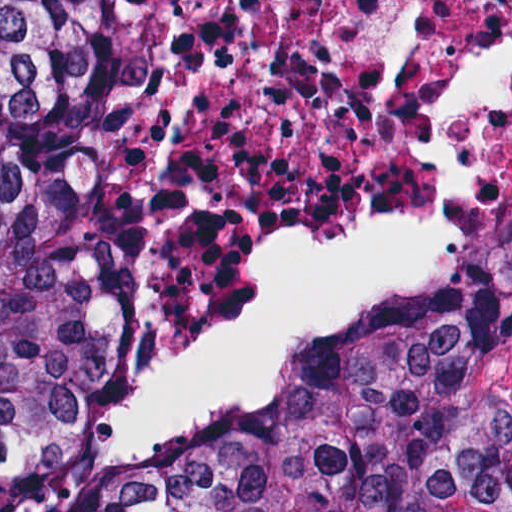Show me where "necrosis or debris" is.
Instances as JSON below:
<instances>
[{
  "mask_svg": "<svg viewBox=\"0 0 512 512\" xmlns=\"http://www.w3.org/2000/svg\"><path fill=\"white\" fill-rule=\"evenodd\" d=\"M107 213L94 443L161 476L512 269V0H67Z\"/></svg>",
  "mask_w": 512,
  "mask_h": 512,
  "instance_id": "necrosis-or-debris-1",
  "label": "necrosis or debris"
}]
</instances>
